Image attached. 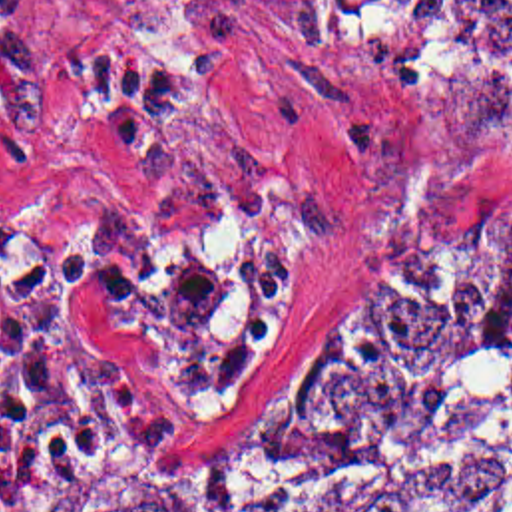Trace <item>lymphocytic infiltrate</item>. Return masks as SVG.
Masks as SVG:
<instances>
[{
	"label": "lymphocytic infiltrate",
	"mask_w": 512,
	"mask_h": 512,
	"mask_svg": "<svg viewBox=\"0 0 512 512\" xmlns=\"http://www.w3.org/2000/svg\"><path fill=\"white\" fill-rule=\"evenodd\" d=\"M39 45L37 2L0 0V75L27 71ZM79 282H97L126 306L142 298L128 271L33 227L0 199V448L11 428L47 414L104 428L148 420V398L104 372L73 332L65 294Z\"/></svg>",
	"instance_id": "f902f5d3"
}]
</instances>
